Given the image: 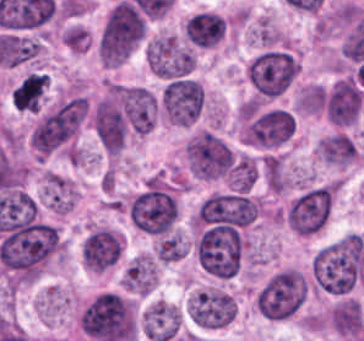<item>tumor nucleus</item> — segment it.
Masks as SVG:
<instances>
[{"mask_svg":"<svg viewBox=\"0 0 364 341\" xmlns=\"http://www.w3.org/2000/svg\"><path fill=\"white\" fill-rule=\"evenodd\" d=\"M128 216L134 228L154 235L172 233L178 217L174 186L162 178H149L134 194Z\"/></svg>","mask_w":364,"mask_h":341,"instance_id":"1","label":"tumor nucleus"},{"mask_svg":"<svg viewBox=\"0 0 364 341\" xmlns=\"http://www.w3.org/2000/svg\"><path fill=\"white\" fill-rule=\"evenodd\" d=\"M145 23L129 1H116L108 11L97 41V54L106 65H118L144 35Z\"/></svg>","mask_w":364,"mask_h":341,"instance_id":"2","label":"tumor nucleus"},{"mask_svg":"<svg viewBox=\"0 0 364 341\" xmlns=\"http://www.w3.org/2000/svg\"><path fill=\"white\" fill-rule=\"evenodd\" d=\"M298 72L297 56L283 49H263L245 65L246 81L257 99L285 92Z\"/></svg>","mask_w":364,"mask_h":341,"instance_id":"3","label":"tumor nucleus"},{"mask_svg":"<svg viewBox=\"0 0 364 341\" xmlns=\"http://www.w3.org/2000/svg\"><path fill=\"white\" fill-rule=\"evenodd\" d=\"M306 290L301 270L285 266L266 278L253 301L264 318L279 320L300 309Z\"/></svg>","mask_w":364,"mask_h":341,"instance_id":"4","label":"tumor nucleus"},{"mask_svg":"<svg viewBox=\"0 0 364 341\" xmlns=\"http://www.w3.org/2000/svg\"><path fill=\"white\" fill-rule=\"evenodd\" d=\"M337 187L334 182L310 185L287 203L284 222L294 233L311 235L329 221Z\"/></svg>","mask_w":364,"mask_h":341,"instance_id":"5","label":"tumor nucleus"},{"mask_svg":"<svg viewBox=\"0 0 364 341\" xmlns=\"http://www.w3.org/2000/svg\"><path fill=\"white\" fill-rule=\"evenodd\" d=\"M183 154L188 168L199 178L214 179L230 172L235 156L224 140L209 129L190 135Z\"/></svg>","mask_w":364,"mask_h":341,"instance_id":"6","label":"tumor nucleus"},{"mask_svg":"<svg viewBox=\"0 0 364 341\" xmlns=\"http://www.w3.org/2000/svg\"><path fill=\"white\" fill-rule=\"evenodd\" d=\"M236 297L219 286L196 291L187 299L188 318L203 327H221L235 319Z\"/></svg>","mask_w":364,"mask_h":341,"instance_id":"7","label":"tumor nucleus"},{"mask_svg":"<svg viewBox=\"0 0 364 341\" xmlns=\"http://www.w3.org/2000/svg\"><path fill=\"white\" fill-rule=\"evenodd\" d=\"M203 104L202 87L192 78H172L162 89L161 106L166 118L189 125L199 116Z\"/></svg>","mask_w":364,"mask_h":341,"instance_id":"8","label":"tumor nucleus"},{"mask_svg":"<svg viewBox=\"0 0 364 341\" xmlns=\"http://www.w3.org/2000/svg\"><path fill=\"white\" fill-rule=\"evenodd\" d=\"M146 61L155 75L177 77L194 65L193 51L176 35H156L145 49Z\"/></svg>","mask_w":364,"mask_h":341,"instance_id":"9","label":"tumor nucleus"},{"mask_svg":"<svg viewBox=\"0 0 364 341\" xmlns=\"http://www.w3.org/2000/svg\"><path fill=\"white\" fill-rule=\"evenodd\" d=\"M293 129V117L286 109L271 108L253 118L242 133L247 143L278 146Z\"/></svg>","mask_w":364,"mask_h":341,"instance_id":"10","label":"tumor nucleus"},{"mask_svg":"<svg viewBox=\"0 0 364 341\" xmlns=\"http://www.w3.org/2000/svg\"><path fill=\"white\" fill-rule=\"evenodd\" d=\"M183 310L165 300L150 302L142 312L143 334L151 341H171L181 334Z\"/></svg>","mask_w":364,"mask_h":341,"instance_id":"11","label":"tumor nucleus"},{"mask_svg":"<svg viewBox=\"0 0 364 341\" xmlns=\"http://www.w3.org/2000/svg\"><path fill=\"white\" fill-rule=\"evenodd\" d=\"M157 266L151 254L133 257L123 272L122 288L126 292L145 295L156 286Z\"/></svg>","mask_w":364,"mask_h":341,"instance_id":"12","label":"tumor nucleus"},{"mask_svg":"<svg viewBox=\"0 0 364 341\" xmlns=\"http://www.w3.org/2000/svg\"><path fill=\"white\" fill-rule=\"evenodd\" d=\"M250 38L253 43L267 46H281L287 40L280 26L272 18L263 15L252 24Z\"/></svg>","mask_w":364,"mask_h":341,"instance_id":"13","label":"tumor nucleus"},{"mask_svg":"<svg viewBox=\"0 0 364 341\" xmlns=\"http://www.w3.org/2000/svg\"><path fill=\"white\" fill-rule=\"evenodd\" d=\"M257 176V162L252 156L241 154L231 169L229 185L236 190H249Z\"/></svg>","mask_w":364,"mask_h":341,"instance_id":"14","label":"tumor nucleus"}]
</instances>
